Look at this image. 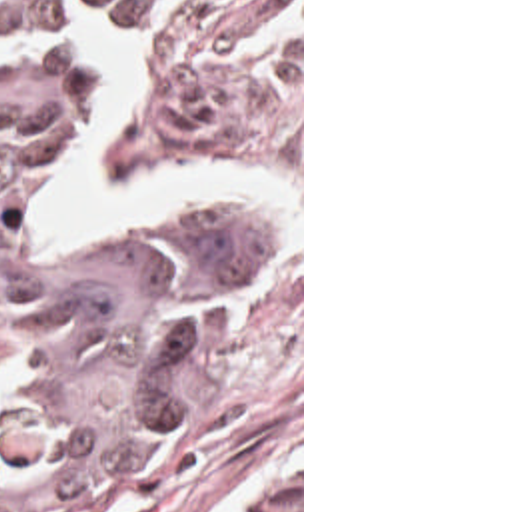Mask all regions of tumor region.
<instances>
[{"mask_svg":"<svg viewBox=\"0 0 512 512\" xmlns=\"http://www.w3.org/2000/svg\"><path fill=\"white\" fill-rule=\"evenodd\" d=\"M116 0H0V304L32 348L0 384V512H70L182 418L230 272L274 250L264 208L196 204L122 248L40 258L14 224L64 152L78 42ZM252 512H300V485Z\"/></svg>","mask_w":512,"mask_h":512,"instance_id":"e687c5a6","label":"tumor region"}]
</instances>
